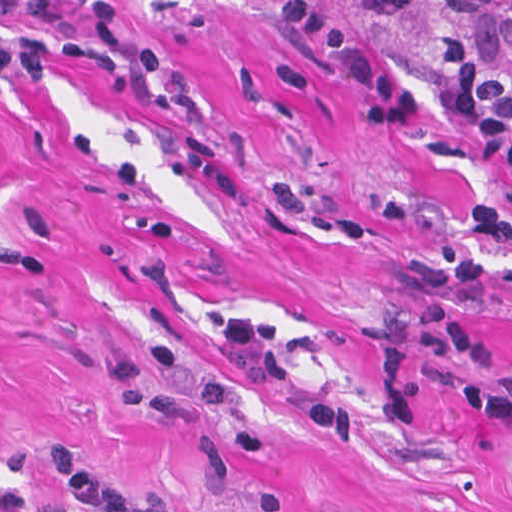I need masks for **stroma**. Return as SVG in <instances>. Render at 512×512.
I'll return each instance as SVG.
<instances>
[{
  "label": "stroma",
  "mask_w": 512,
  "mask_h": 512,
  "mask_svg": "<svg viewBox=\"0 0 512 512\" xmlns=\"http://www.w3.org/2000/svg\"><path fill=\"white\" fill-rule=\"evenodd\" d=\"M187 85L129 64L0 75V512H72L43 454L172 512H512V427L452 402L481 369L406 349L411 265L512 183L437 69L422 1L369 18L310 0L422 94L415 128L362 125L287 0H108ZM92 0H43L89 29ZM34 30L45 26L0 11ZM274 322L284 385L222 356L231 315ZM512 367V239L464 315Z\"/></svg>",
  "instance_id": "stroma-1"
}]
</instances>
